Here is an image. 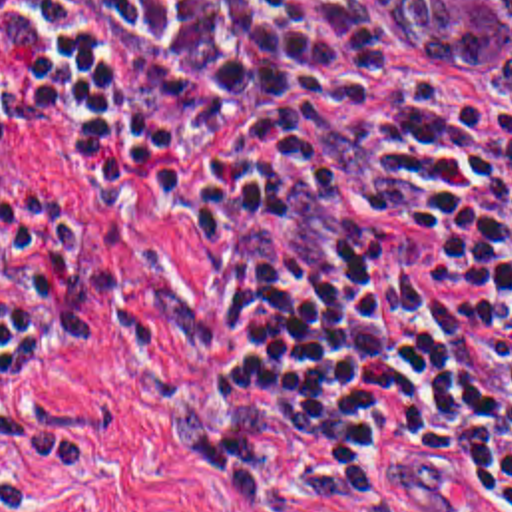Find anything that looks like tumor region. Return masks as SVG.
<instances>
[{
  "mask_svg": "<svg viewBox=\"0 0 512 512\" xmlns=\"http://www.w3.org/2000/svg\"><path fill=\"white\" fill-rule=\"evenodd\" d=\"M414 53L442 73L492 65L496 99L512 113V0H372Z\"/></svg>",
  "mask_w": 512,
  "mask_h": 512,
  "instance_id": "1",
  "label": "tumor region"
}]
</instances>
